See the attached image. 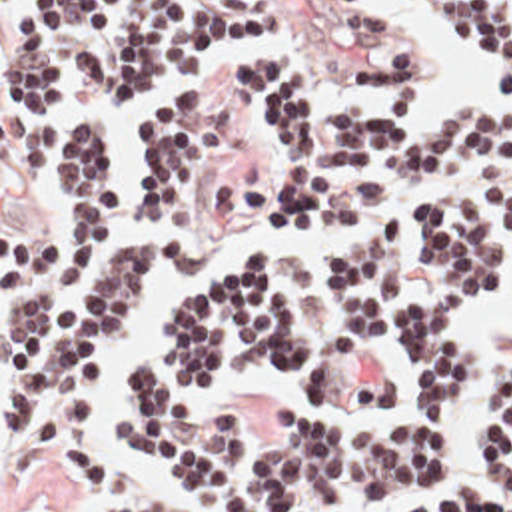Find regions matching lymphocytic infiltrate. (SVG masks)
Here are the masks:
<instances>
[{
    "label": "lymphocytic infiltrate",
    "mask_w": 512,
    "mask_h": 512,
    "mask_svg": "<svg viewBox=\"0 0 512 512\" xmlns=\"http://www.w3.org/2000/svg\"><path fill=\"white\" fill-rule=\"evenodd\" d=\"M435 1L512 89V0ZM2 25V137L26 178H52L48 248L2 312V446L20 460L48 446L84 502H126L142 492L138 472L92 448L98 358L136 334L158 272L180 264L166 232L192 224L236 146L200 79L280 33L282 0H2ZM353 67L399 99L321 107L294 49L246 59L238 87L282 137V178L250 238L359 224L244 256L184 306L162 358L120 364L132 412L106 440L212 512H347L429 474L461 374L455 306L511 260L512 129L475 103L417 127L411 31ZM132 148L148 236L132 232L112 158ZM393 340L411 352L407 406L383 424H325L313 408L377 412L401 398L405 378L379 348ZM248 364L296 382L301 400L276 408L282 426L252 430L250 408L194 396ZM489 466L512 498V368ZM399 512L475 510L433 494Z\"/></svg>",
    "instance_id": "lymphocytic-infiltrate-1"
}]
</instances>
